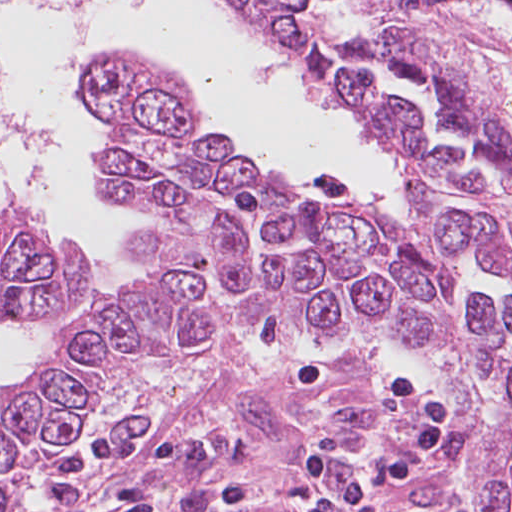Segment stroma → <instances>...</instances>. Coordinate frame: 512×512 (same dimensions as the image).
<instances>
[{"label": "stroma", "mask_w": 512, "mask_h": 512, "mask_svg": "<svg viewBox=\"0 0 512 512\" xmlns=\"http://www.w3.org/2000/svg\"><path fill=\"white\" fill-rule=\"evenodd\" d=\"M402 15L433 48L498 89L512 110V0H403ZM124 56L186 99L140 60ZM96 66L83 90L106 130L100 160L110 146L111 126L85 90ZM280 183L305 197L381 203L391 209H408L415 196L410 186L403 201L385 204L323 189L297 191ZM82 262L90 285L100 271L98 262L84 251ZM111 298L95 302L74 320ZM307 357L329 362L332 384L316 391L295 388L293 374ZM407 372L421 374L436 387L455 413L456 425L419 480L380 495L383 511L485 512L475 407L454 378L401 337H353L277 351H167L132 362L98 387L58 448L104 434L182 439L189 445L186 463L150 482L159 512H291L305 492L295 470L298 457L320 428L339 430L356 454L401 439L406 409L393 402L389 387ZM114 471L113 466L96 470L86 512H110Z\"/></svg>", "instance_id": "1"}]
</instances>
